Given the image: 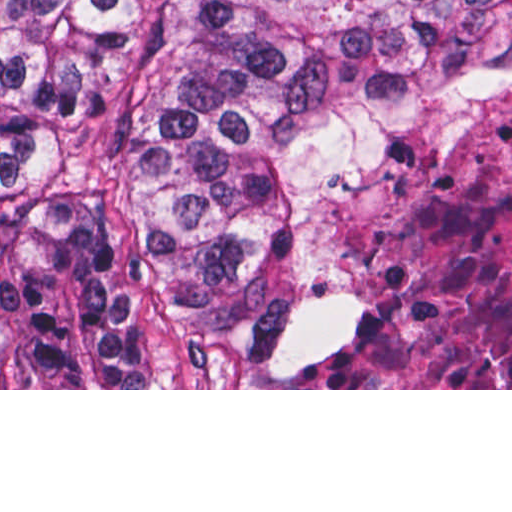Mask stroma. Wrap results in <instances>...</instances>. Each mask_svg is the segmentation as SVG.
I'll list each match as a JSON object with an SVG mask.
<instances>
[{
    "mask_svg": "<svg viewBox=\"0 0 512 512\" xmlns=\"http://www.w3.org/2000/svg\"><path fill=\"white\" fill-rule=\"evenodd\" d=\"M512 110V84L500 86L479 109H442L393 97H357L352 125L328 148L314 172L303 206L297 238V263L321 274L337 271L333 252L357 227V211L347 203L328 201L337 167L382 148L396 131L415 122H449ZM347 301L349 328L317 359L309 358L319 303ZM367 325V297L357 293H322L305 316L294 358L282 370H263L253 363L218 355L201 361L182 389H0V390H512V388H303L302 372L319 358L354 340Z\"/></svg>",
    "mask_w": 512,
    "mask_h": 512,
    "instance_id": "obj_1",
    "label": "stroma"
}]
</instances>
